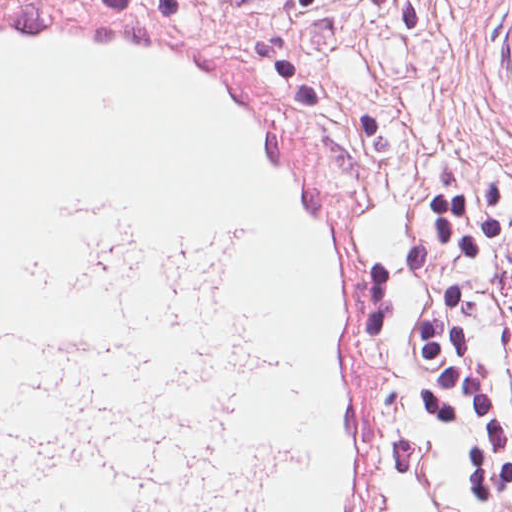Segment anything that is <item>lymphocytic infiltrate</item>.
Wrapping results in <instances>:
<instances>
[{
    "instance_id": "f902f5d3",
    "label": "lymphocytic infiltrate",
    "mask_w": 512,
    "mask_h": 512,
    "mask_svg": "<svg viewBox=\"0 0 512 512\" xmlns=\"http://www.w3.org/2000/svg\"><path fill=\"white\" fill-rule=\"evenodd\" d=\"M512 167L446 160L392 267L359 283L386 477L512 500Z\"/></svg>"
}]
</instances>
